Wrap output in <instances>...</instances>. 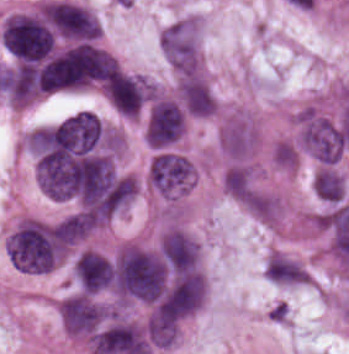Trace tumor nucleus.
Returning <instances> with one entry per match:
<instances>
[{
	"label": "tumor nucleus",
	"mask_w": 349,
	"mask_h": 354,
	"mask_svg": "<svg viewBox=\"0 0 349 354\" xmlns=\"http://www.w3.org/2000/svg\"><path fill=\"white\" fill-rule=\"evenodd\" d=\"M159 48L174 70H200V23L198 17L181 16L158 34Z\"/></svg>",
	"instance_id": "obj_3"
},
{
	"label": "tumor nucleus",
	"mask_w": 349,
	"mask_h": 354,
	"mask_svg": "<svg viewBox=\"0 0 349 354\" xmlns=\"http://www.w3.org/2000/svg\"><path fill=\"white\" fill-rule=\"evenodd\" d=\"M185 129V110L170 96L157 95L150 99L143 134L150 148H170Z\"/></svg>",
	"instance_id": "obj_5"
},
{
	"label": "tumor nucleus",
	"mask_w": 349,
	"mask_h": 354,
	"mask_svg": "<svg viewBox=\"0 0 349 354\" xmlns=\"http://www.w3.org/2000/svg\"><path fill=\"white\" fill-rule=\"evenodd\" d=\"M195 162L177 149L159 148L149 160L147 182L167 199L187 193L196 177Z\"/></svg>",
	"instance_id": "obj_2"
},
{
	"label": "tumor nucleus",
	"mask_w": 349,
	"mask_h": 354,
	"mask_svg": "<svg viewBox=\"0 0 349 354\" xmlns=\"http://www.w3.org/2000/svg\"><path fill=\"white\" fill-rule=\"evenodd\" d=\"M311 187L313 194L331 205L344 197V177L335 169L317 168L312 175Z\"/></svg>",
	"instance_id": "obj_11"
},
{
	"label": "tumor nucleus",
	"mask_w": 349,
	"mask_h": 354,
	"mask_svg": "<svg viewBox=\"0 0 349 354\" xmlns=\"http://www.w3.org/2000/svg\"><path fill=\"white\" fill-rule=\"evenodd\" d=\"M221 181L232 199L246 200L254 187L253 170L243 162L233 163L224 170Z\"/></svg>",
	"instance_id": "obj_10"
},
{
	"label": "tumor nucleus",
	"mask_w": 349,
	"mask_h": 354,
	"mask_svg": "<svg viewBox=\"0 0 349 354\" xmlns=\"http://www.w3.org/2000/svg\"><path fill=\"white\" fill-rule=\"evenodd\" d=\"M264 280L273 285L300 286L308 281L306 270L295 259L276 251L264 257Z\"/></svg>",
	"instance_id": "obj_9"
},
{
	"label": "tumor nucleus",
	"mask_w": 349,
	"mask_h": 354,
	"mask_svg": "<svg viewBox=\"0 0 349 354\" xmlns=\"http://www.w3.org/2000/svg\"><path fill=\"white\" fill-rule=\"evenodd\" d=\"M39 12L60 34L73 38L98 36L100 27L94 16L80 5L64 0L46 1Z\"/></svg>",
	"instance_id": "obj_6"
},
{
	"label": "tumor nucleus",
	"mask_w": 349,
	"mask_h": 354,
	"mask_svg": "<svg viewBox=\"0 0 349 354\" xmlns=\"http://www.w3.org/2000/svg\"><path fill=\"white\" fill-rule=\"evenodd\" d=\"M117 312V305L80 290L58 301L63 328L83 339Z\"/></svg>",
	"instance_id": "obj_4"
},
{
	"label": "tumor nucleus",
	"mask_w": 349,
	"mask_h": 354,
	"mask_svg": "<svg viewBox=\"0 0 349 354\" xmlns=\"http://www.w3.org/2000/svg\"><path fill=\"white\" fill-rule=\"evenodd\" d=\"M269 158L271 164L280 170L295 168L297 160L291 148L284 141H276L270 147Z\"/></svg>",
	"instance_id": "obj_12"
},
{
	"label": "tumor nucleus",
	"mask_w": 349,
	"mask_h": 354,
	"mask_svg": "<svg viewBox=\"0 0 349 354\" xmlns=\"http://www.w3.org/2000/svg\"><path fill=\"white\" fill-rule=\"evenodd\" d=\"M0 39L17 59H37L53 50V32L37 11H17L5 16Z\"/></svg>",
	"instance_id": "obj_1"
},
{
	"label": "tumor nucleus",
	"mask_w": 349,
	"mask_h": 354,
	"mask_svg": "<svg viewBox=\"0 0 349 354\" xmlns=\"http://www.w3.org/2000/svg\"><path fill=\"white\" fill-rule=\"evenodd\" d=\"M258 140L259 130L254 118L243 112L227 115L220 123L218 145L232 160L250 158Z\"/></svg>",
	"instance_id": "obj_7"
},
{
	"label": "tumor nucleus",
	"mask_w": 349,
	"mask_h": 354,
	"mask_svg": "<svg viewBox=\"0 0 349 354\" xmlns=\"http://www.w3.org/2000/svg\"><path fill=\"white\" fill-rule=\"evenodd\" d=\"M176 100L189 116L206 117L217 111L209 86L196 74L180 75L175 85Z\"/></svg>",
	"instance_id": "obj_8"
}]
</instances>
